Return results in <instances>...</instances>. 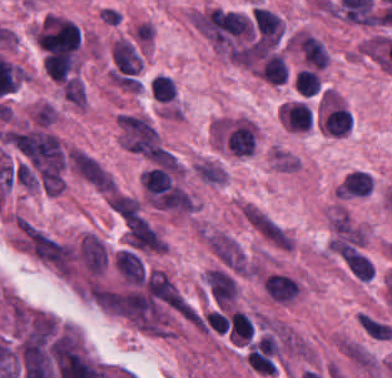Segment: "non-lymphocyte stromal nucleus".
I'll list each match as a JSON object with an SVG mask.
<instances>
[{
	"label": "non-lymphocyte stromal nucleus",
	"instance_id": "5",
	"mask_svg": "<svg viewBox=\"0 0 392 378\" xmlns=\"http://www.w3.org/2000/svg\"><path fill=\"white\" fill-rule=\"evenodd\" d=\"M357 322L368 335L379 340H387L392 332L389 326L365 314H358Z\"/></svg>",
	"mask_w": 392,
	"mask_h": 378
},
{
	"label": "non-lymphocyte stromal nucleus",
	"instance_id": "1",
	"mask_svg": "<svg viewBox=\"0 0 392 378\" xmlns=\"http://www.w3.org/2000/svg\"><path fill=\"white\" fill-rule=\"evenodd\" d=\"M20 248L56 276L69 277L71 245L25 218L15 220Z\"/></svg>",
	"mask_w": 392,
	"mask_h": 378
},
{
	"label": "non-lymphocyte stromal nucleus",
	"instance_id": "2",
	"mask_svg": "<svg viewBox=\"0 0 392 378\" xmlns=\"http://www.w3.org/2000/svg\"><path fill=\"white\" fill-rule=\"evenodd\" d=\"M240 214L247 225L278 248L289 251L294 245L290 232L264 210L244 203Z\"/></svg>",
	"mask_w": 392,
	"mask_h": 378
},
{
	"label": "non-lymphocyte stromal nucleus",
	"instance_id": "4",
	"mask_svg": "<svg viewBox=\"0 0 392 378\" xmlns=\"http://www.w3.org/2000/svg\"><path fill=\"white\" fill-rule=\"evenodd\" d=\"M341 351L351 362L357 367L364 370L374 369L377 360L375 357L362 345L349 339H342L339 344Z\"/></svg>",
	"mask_w": 392,
	"mask_h": 378
},
{
	"label": "non-lymphocyte stromal nucleus",
	"instance_id": "3",
	"mask_svg": "<svg viewBox=\"0 0 392 378\" xmlns=\"http://www.w3.org/2000/svg\"><path fill=\"white\" fill-rule=\"evenodd\" d=\"M79 252L87 271L100 275L105 266V258L99 238L90 233L84 236Z\"/></svg>",
	"mask_w": 392,
	"mask_h": 378
}]
</instances>
